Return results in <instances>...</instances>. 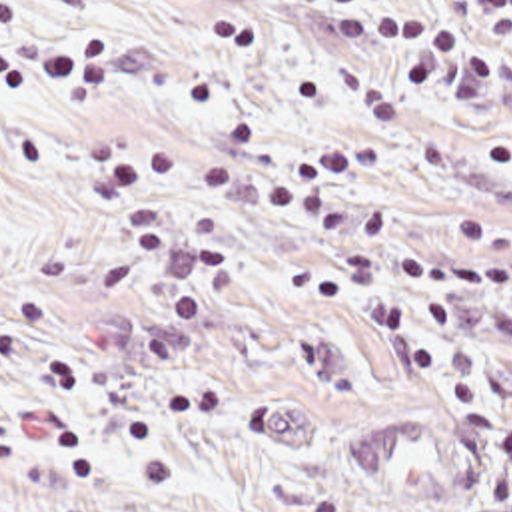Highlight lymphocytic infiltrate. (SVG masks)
<instances>
[{
	"label": "lymphocytic infiltrate",
	"mask_w": 512,
	"mask_h": 512,
	"mask_svg": "<svg viewBox=\"0 0 512 512\" xmlns=\"http://www.w3.org/2000/svg\"><path fill=\"white\" fill-rule=\"evenodd\" d=\"M26 0H0V96L56 94L78 108H98L116 92V48L96 30L38 32ZM469 20L431 30L407 18L341 20L337 44L349 50L383 48L411 56L407 80L419 96L451 90L477 98L499 74L501 50L512 42V0H455ZM86 160L110 212L124 214L126 242L102 262L100 274L116 294L136 288L146 270L170 250L200 252L176 304L158 316L142 353L176 361L194 351L236 284L234 240L194 206L176 224L156 190L206 194L248 212L296 220L349 242L341 268L320 280L316 294L355 324L389 334L443 393L451 411L487 419L493 427L497 469L487 489L489 507H512V421L489 387L449 373L427 336L401 310L399 280L425 312L439 340L463 328L457 300L465 292L512 284V214L477 210L455 214L451 252L415 250L395 242L383 206L339 192L351 178L373 176L387 164L375 142L345 138L276 164L226 166L210 156L114 134L86 140ZM507 260H491V256ZM353 282L349 280V276ZM284 512H345L341 499L296 491Z\"/></svg>",
	"instance_id": "obj_1"
}]
</instances>
